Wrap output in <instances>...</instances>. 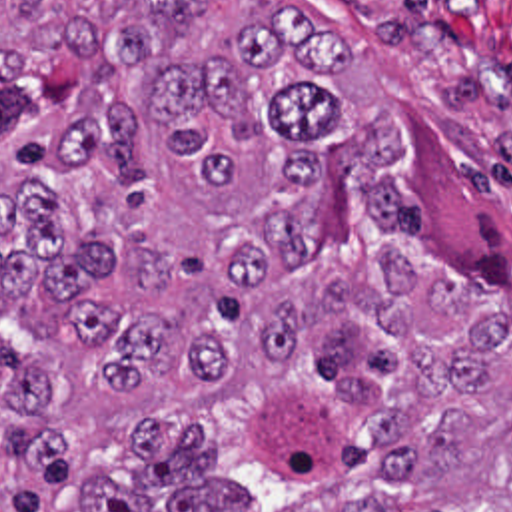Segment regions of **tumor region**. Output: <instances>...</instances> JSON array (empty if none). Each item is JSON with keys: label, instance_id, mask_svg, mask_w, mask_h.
Segmentation results:
<instances>
[{"label": "tumor region", "instance_id": "obj_1", "mask_svg": "<svg viewBox=\"0 0 512 512\" xmlns=\"http://www.w3.org/2000/svg\"><path fill=\"white\" fill-rule=\"evenodd\" d=\"M238 9L0 0V512H512V285L346 43Z\"/></svg>", "mask_w": 512, "mask_h": 512}]
</instances>
